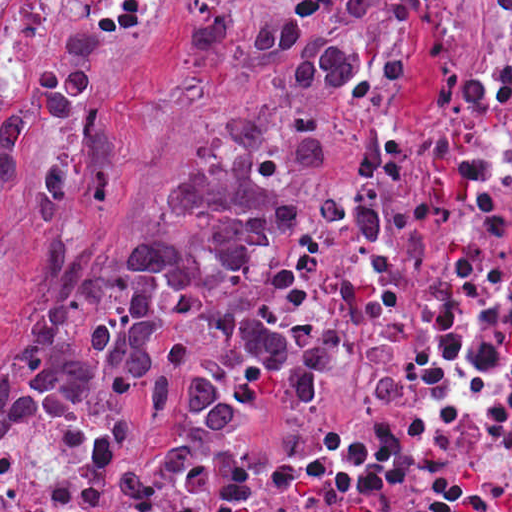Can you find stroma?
Masks as SVG:
<instances>
[{
	"mask_svg": "<svg viewBox=\"0 0 512 512\" xmlns=\"http://www.w3.org/2000/svg\"><path fill=\"white\" fill-rule=\"evenodd\" d=\"M224 274L228 294L235 309L246 318L268 323L243 294L235 275V268L225 271ZM294 336L310 346L318 356L317 392L304 401H282L272 398L253 401L241 413L235 429L225 433H197L169 420L135 414L125 399L109 388H39L27 391L13 401L5 416L0 417V421L7 419L16 405L34 391H61L84 396L112 422L136 435L154 438H254L273 434L313 418L326 408L334 389V368L318 346L311 338Z\"/></svg>",
	"mask_w": 512,
	"mask_h": 512,
	"instance_id": "35a3bbf8",
	"label": "stroma"
}]
</instances>
